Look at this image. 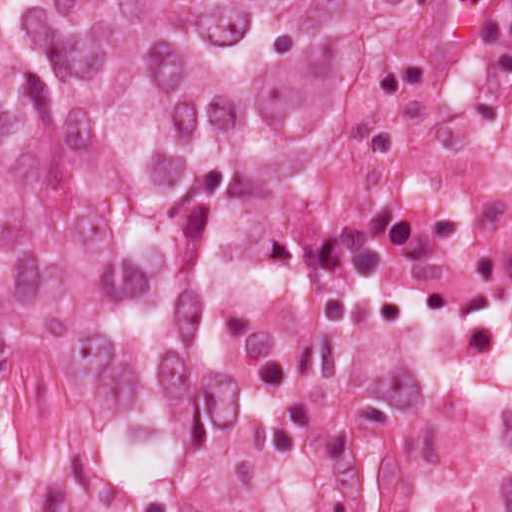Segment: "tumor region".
Listing matches in <instances>:
<instances>
[{
  "label": "tumor region",
  "instance_id": "e687c5a6",
  "mask_svg": "<svg viewBox=\"0 0 512 512\" xmlns=\"http://www.w3.org/2000/svg\"><path fill=\"white\" fill-rule=\"evenodd\" d=\"M360 2L0 1V378L45 355L103 411L164 412L210 209L324 168Z\"/></svg>",
  "mask_w": 512,
  "mask_h": 512
}]
</instances>
